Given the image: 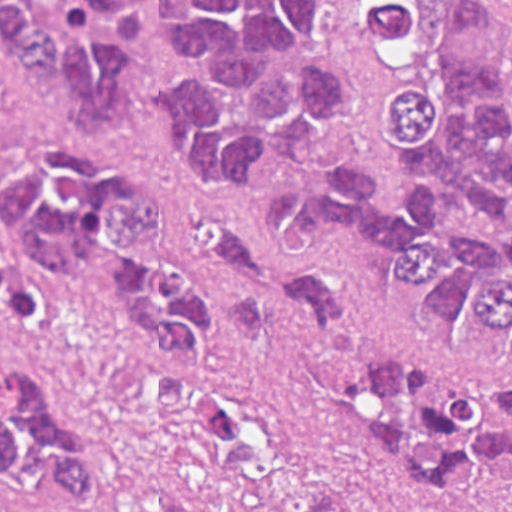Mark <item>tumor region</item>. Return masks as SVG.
Listing matches in <instances>:
<instances>
[{"label":"tumor region","mask_w":512,"mask_h":512,"mask_svg":"<svg viewBox=\"0 0 512 512\" xmlns=\"http://www.w3.org/2000/svg\"><path fill=\"white\" fill-rule=\"evenodd\" d=\"M394 77L386 144L407 210L375 201L372 165L336 162L340 78L323 69V0H0L19 69L69 84L87 130L137 118L133 52L180 69L155 94L181 171L249 192L292 163L319 178L271 197L295 244L375 233L400 255L390 305L475 364H512V94L501 0H355ZM174 214L147 177L72 139L0 158V323L59 299L191 369L223 342L208 293L174 263ZM204 267L237 335L296 374L380 506L358 510L261 413L184 387L172 428L205 460L220 512H512V372L427 354L324 291L272 243L208 223ZM0 512H106L97 457L42 371L0 353Z\"/></svg>","instance_id":"e687c5a6"}]
</instances>
